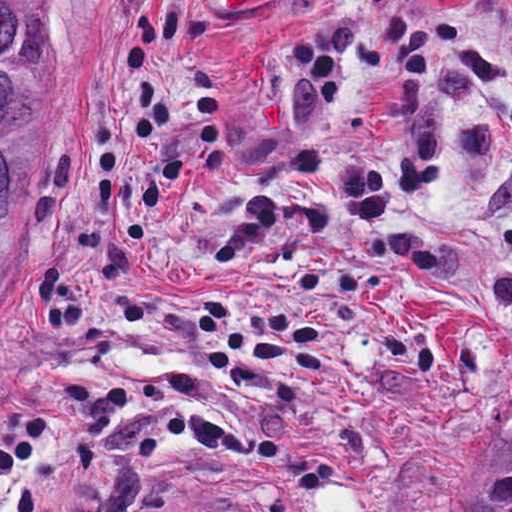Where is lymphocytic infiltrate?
Here are the masks:
<instances>
[{
  "instance_id": "1",
  "label": "lymphocytic infiltrate",
  "mask_w": 512,
  "mask_h": 512,
  "mask_svg": "<svg viewBox=\"0 0 512 512\" xmlns=\"http://www.w3.org/2000/svg\"><path fill=\"white\" fill-rule=\"evenodd\" d=\"M184 22L180 5H175L147 13L134 31L132 27L125 57V89L136 114L130 134L141 145L157 147L170 119L185 116L193 127L205 171H222V111L216 75L202 62L190 65L187 82L177 93L162 82L160 53L182 34ZM294 54L314 81L319 111H335V48L300 36ZM354 166L337 172L334 190L352 219L379 221L390 210V187ZM117 170L116 126L99 121L94 138L99 211L115 204ZM276 223L277 204L268 195L249 192L239 198L212 243L206 267L217 273H236L252 265ZM52 424L53 415L41 407H19L0 416V474H11L18 463L42 447Z\"/></svg>"
}]
</instances>
